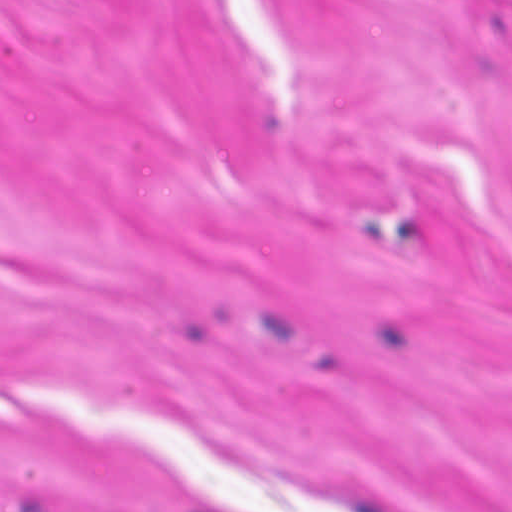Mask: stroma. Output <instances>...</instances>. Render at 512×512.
<instances>
[{"mask_svg": "<svg viewBox=\"0 0 512 512\" xmlns=\"http://www.w3.org/2000/svg\"><path fill=\"white\" fill-rule=\"evenodd\" d=\"M0 512H512V0H0Z\"/></svg>", "mask_w": 512, "mask_h": 512, "instance_id": "obj_1", "label": "stroma"}]
</instances>
